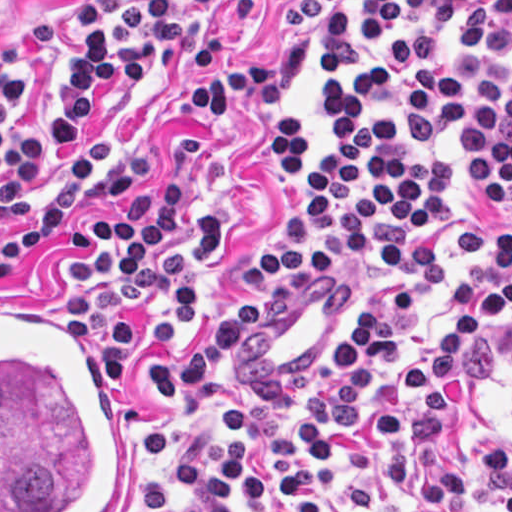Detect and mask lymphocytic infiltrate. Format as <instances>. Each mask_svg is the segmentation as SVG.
<instances>
[{"mask_svg":"<svg viewBox=\"0 0 512 512\" xmlns=\"http://www.w3.org/2000/svg\"><path fill=\"white\" fill-rule=\"evenodd\" d=\"M185 0H76V33L54 87L43 96L36 122L25 116L23 76L0 68V216L21 204L30 180L76 148L113 95L144 80L147 53L155 68L186 43ZM205 13H222L250 0H189ZM274 20L298 27L269 65L211 74L206 85L184 89L195 110H235L249 91L275 102L299 81L307 63L323 56L327 81L317 120L327 144L307 149L291 113L278 118L274 149L280 177L305 176L285 198L269 240L248 257L252 278L293 276L346 255L395 278L443 271L441 246L409 228L443 230L450 218L452 166L437 148L449 129L461 134L464 206L475 227L493 237V269L456 276L453 321L435 334L428 353L406 368L410 390L422 401L408 428L401 413L366 415V393L403 348L401 324L413 300L405 287L349 323L346 342L333 350L310 390V411L299 426L293 475L251 463L243 440L251 409L220 373L244 335L262 316L251 295L215 319L186 357L149 359L152 399L159 407L196 392L217 414L219 432L207 456L180 462L179 490L201 494L187 512H228L230 491L240 506L272 494L286 512H323L337 453L351 426L389 439L382 456L386 488L412 490L400 512H423L465 493L467 479L485 476L505 512H512V450L478 443L466 469H446L434 444L439 378H457L476 339L512 314V223L485 211L512 212V69L480 54L512 56V0H281ZM105 204H132L121 218H101L92 237L98 257L71 261L75 277L111 282L76 294L69 316L89 343H103L99 364L121 389L133 353V326L115 314L164 302L167 314L146 323V339L174 347L184 331L191 281L222 250L214 211L195 208L192 237L169 241L192 193L191 175L165 174L155 186L140 175H107L84 154L54 199L0 250V282L46 244L64 237L67 215L85 194ZM452 327H456L450 335Z\"/></svg>","mask_w":512,"mask_h":512,"instance_id":"lymphocytic-infiltrate-1","label":"lymphocytic infiltrate"}]
</instances>
